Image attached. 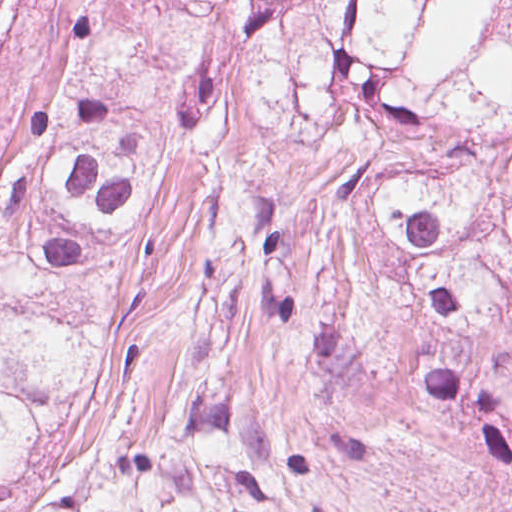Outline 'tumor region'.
<instances>
[{"label": "tumor region", "instance_id": "obj_1", "mask_svg": "<svg viewBox=\"0 0 512 512\" xmlns=\"http://www.w3.org/2000/svg\"><path fill=\"white\" fill-rule=\"evenodd\" d=\"M461 0H61V31L0 124V512L52 417L123 353L98 278L166 176L217 157L219 95L300 148L333 141L340 191L256 195L247 251L264 316L299 332L334 393ZM15 0H0V40ZM316 446L200 403L159 442L72 451L44 512H295Z\"/></svg>", "mask_w": 512, "mask_h": 512}]
</instances>
